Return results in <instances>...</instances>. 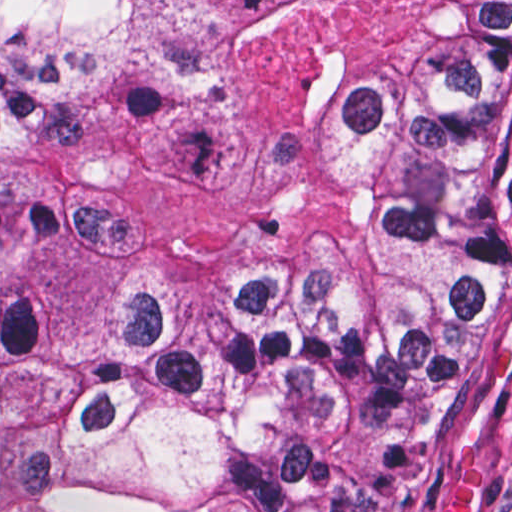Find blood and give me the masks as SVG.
I'll use <instances>...</instances> for the list:
<instances>
[{
  "label": "blood",
  "mask_w": 512,
  "mask_h": 512,
  "mask_svg": "<svg viewBox=\"0 0 512 512\" xmlns=\"http://www.w3.org/2000/svg\"><path fill=\"white\" fill-rule=\"evenodd\" d=\"M512 363V326L490 351V375L501 378ZM442 512H475V471L463 476L453 487Z\"/></svg>",
  "instance_id": "blood-1"
}]
</instances>
